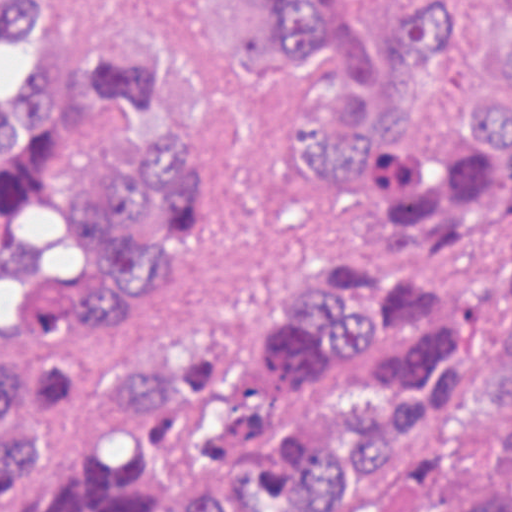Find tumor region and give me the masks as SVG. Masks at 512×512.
I'll return each mask as SVG.
<instances>
[{"mask_svg":"<svg viewBox=\"0 0 512 512\" xmlns=\"http://www.w3.org/2000/svg\"><path fill=\"white\" fill-rule=\"evenodd\" d=\"M259 1L327 72L288 130L345 238L208 348L119 332L206 211L181 60L103 36L0 93V338L34 356L0 353V512H512V94L425 108L457 36L434 10L370 33ZM49 2L0 0V39Z\"/></svg>","mask_w":512,"mask_h":512,"instance_id":"e687c5a6","label":"tumor region"}]
</instances>
